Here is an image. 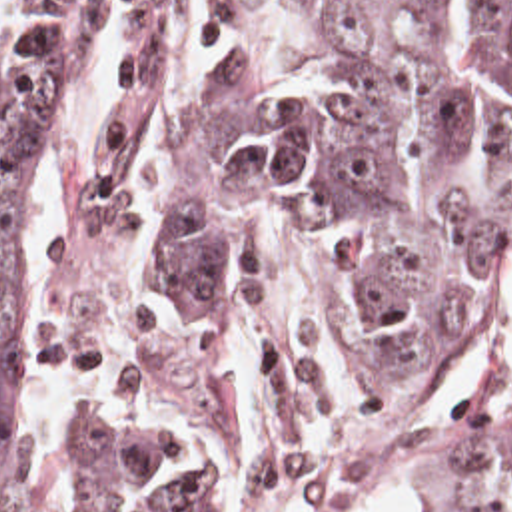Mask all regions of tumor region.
<instances>
[{
	"label": "tumor region",
	"instance_id": "obj_1",
	"mask_svg": "<svg viewBox=\"0 0 512 512\" xmlns=\"http://www.w3.org/2000/svg\"><path fill=\"white\" fill-rule=\"evenodd\" d=\"M176 0H0V512H18L10 273L20 231L104 29L134 75L94 153L92 201L124 199L160 125L154 31ZM324 37L322 97L270 69L208 87L184 129L160 245L192 305L228 301L288 249L374 375L452 343L512 259V0H292ZM94 512H254L210 444L156 436L128 403L90 413ZM436 512H512V393L452 422Z\"/></svg>",
	"mask_w": 512,
	"mask_h": 512
}]
</instances>
